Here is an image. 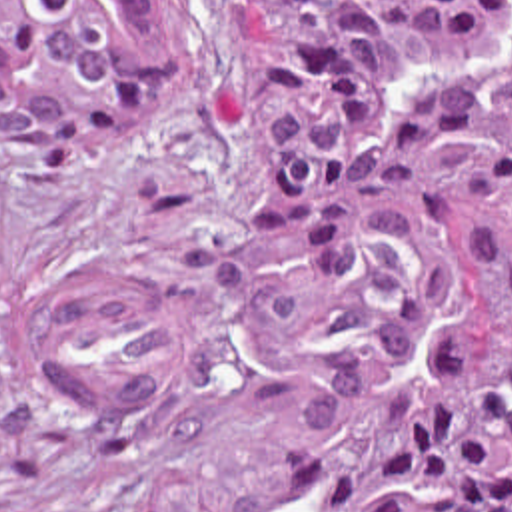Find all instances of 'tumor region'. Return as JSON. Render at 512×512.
<instances>
[{
	"instance_id": "e687c5a6",
	"label": "tumor region",
	"mask_w": 512,
	"mask_h": 512,
	"mask_svg": "<svg viewBox=\"0 0 512 512\" xmlns=\"http://www.w3.org/2000/svg\"><path fill=\"white\" fill-rule=\"evenodd\" d=\"M178 0H0V152L72 166L174 80ZM268 150L236 212L336 282L280 512H512V0H242ZM18 308L0 202V348Z\"/></svg>"
}]
</instances>
